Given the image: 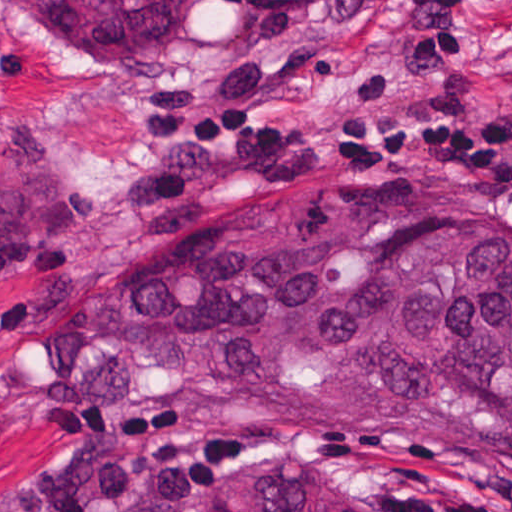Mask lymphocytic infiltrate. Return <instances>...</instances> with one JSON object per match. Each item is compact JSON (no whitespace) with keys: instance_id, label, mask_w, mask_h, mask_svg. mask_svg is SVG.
I'll return each instance as SVG.
<instances>
[{"instance_id":"f902f5d3","label":"lymphocytic infiltrate","mask_w":512,"mask_h":512,"mask_svg":"<svg viewBox=\"0 0 512 512\" xmlns=\"http://www.w3.org/2000/svg\"><path fill=\"white\" fill-rule=\"evenodd\" d=\"M406 17L408 67L439 69L472 46L459 0H377ZM286 157H386L449 166L512 193V104H364L332 124L258 121L211 96L174 103L154 162L113 192L123 220H151L232 191ZM67 462L38 494L40 512H187L240 443L229 423L159 413L132 426L51 428ZM383 512H512V493L400 491Z\"/></svg>"}]
</instances>
